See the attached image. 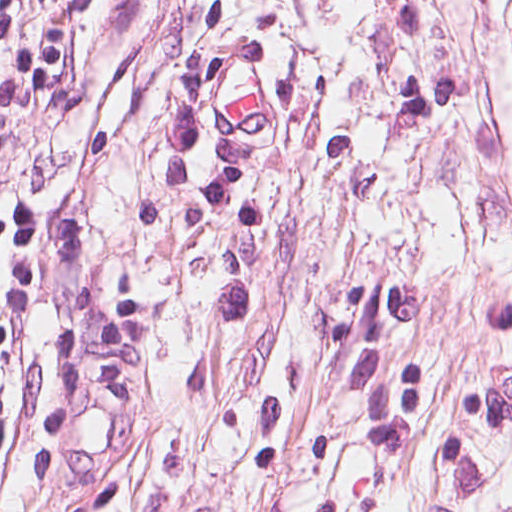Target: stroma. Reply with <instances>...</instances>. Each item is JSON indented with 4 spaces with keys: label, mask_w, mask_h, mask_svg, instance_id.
I'll return each instance as SVG.
<instances>
[{
    "label": "stroma",
    "mask_w": 512,
    "mask_h": 512,
    "mask_svg": "<svg viewBox=\"0 0 512 512\" xmlns=\"http://www.w3.org/2000/svg\"><path fill=\"white\" fill-rule=\"evenodd\" d=\"M71 2L0 512H512V0Z\"/></svg>",
    "instance_id": "stroma-1"
}]
</instances>
